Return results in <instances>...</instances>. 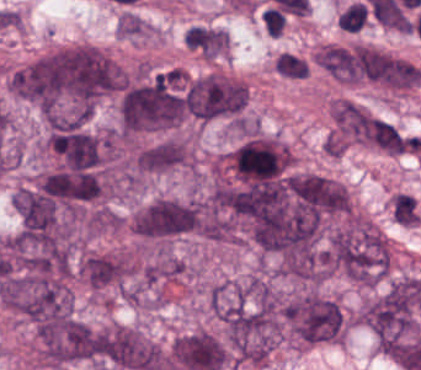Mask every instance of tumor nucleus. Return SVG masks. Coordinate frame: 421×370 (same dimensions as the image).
Here are the masks:
<instances>
[{
	"label": "tumor nucleus",
	"instance_id": "2f306a5c",
	"mask_svg": "<svg viewBox=\"0 0 421 370\" xmlns=\"http://www.w3.org/2000/svg\"><path fill=\"white\" fill-rule=\"evenodd\" d=\"M116 63L95 45L51 50L41 57L37 108L88 116L117 91Z\"/></svg>",
	"mask_w": 421,
	"mask_h": 370
},
{
	"label": "tumor nucleus",
	"instance_id": "8643909e",
	"mask_svg": "<svg viewBox=\"0 0 421 370\" xmlns=\"http://www.w3.org/2000/svg\"><path fill=\"white\" fill-rule=\"evenodd\" d=\"M279 334L300 346L339 341L344 335V314L334 298L310 289L293 292L280 305Z\"/></svg>",
	"mask_w": 421,
	"mask_h": 370
},
{
	"label": "tumor nucleus",
	"instance_id": "5ab6c2c4",
	"mask_svg": "<svg viewBox=\"0 0 421 370\" xmlns=\"http://www.w3.org/2000/svg\"><path fill=\"white\" fill-rule=\"evenodd\" d=\"M126 225L131 234L142 241L165 240L195 233L196 201L157 196L134 208Z\"/></svg>",
	"mask_w": 421,
	"mask_h": 370
},
{
	"label": "tumor nucleus",
	"instance_id": "2cbd58db",
	"mask_svg": "<svg viewBox=\"0 0 421 370\" xmlns=\"http://www.w3.org/2000/svg\"><path fill=\"white\" fill-rule=\"evenodd\" d=\"M331 131L348 145L375 147V114L343 97L330 104Z\"/></svg>",
	"mask_w": 421,
	"mask_h": 370
},
{
	"label": "tumor nucleus",
	"instance_id": "3d1891a8",
	"mask_svg": "<svg viewBox=\"0 0 421 370\" xmlns=\"http://www.w3.org/2000/svg\"><path fill=\"white\" fill-rule=\"evenodd\" d=\"M369 138L370 144L389 155L411 151L412 138L386 118L371 116Z\"/></svg>",
	"mask_w": 421,
	"mask_h": 370
},
{
	"label": "tumor nucleus",
	"instance_id": "2083b535",
	"mask_svg": "<svg viewBox=\"0 0 421 370\" xmlns=\"http://www.w3.org/2000/svg\"><path fill=\"white\" fill-rule=\"evenodd\" d=\"M156 28L135 11H121L116 17L114 32L127 40L151 37Z\"/></svg>",
	"mask_w": 421,
	"mask_h": 370
},
{
	"label": "tumor nucleus",
	"instance_id": "8087334f",
	"mask_svg": "<svg viewBox=\"0 0 421 370\" xmlns=\"http://www.w3.org/2000/svg\"><path fill=\"white\" fill-rule=\"evenodd\" d=\"M273 64L275 74L286 80H300L310 71L306 58L295 53L282 52L274 58Z\"/></svg>",
	"mask_w": 421,
	"mask_h": 370
},
{
	"label": "tumor nucleus",
	"instance_id": "c2bd9aea",
	"mask_svg": "<svg viewBox=\"0 0 421 370\" xmlns=\"http://www.w3.org/2000/svg\"><path fill=\"white\" fill-rule=\"evenodd\" d=\"M322 149L327 155L342 157L345 152V142L343 137L332 130L323 140Z\"/></svg>",
	"mask_w": 421,
	"mask_h": 370
}]
</instances>
